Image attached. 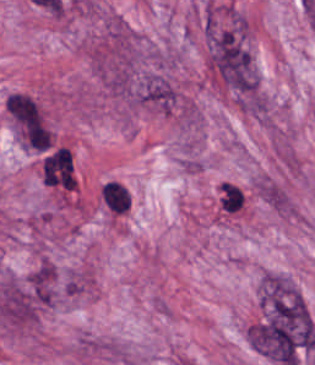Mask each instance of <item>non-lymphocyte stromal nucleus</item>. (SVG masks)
<instances>
[{
    "label": "non-lymphocyte stromal nucleus",
    "instance_id": "non-lymphocyte-stromal-nucleus-1",
    "mask_svg": "<svg viewBox=\"0 0 315 365\" xmlns=\"http://www.w3.org/2000/svg\"><path fill=\"white\" fill-rule=\"evenodd\" d=\"M7 109L23 144L36 151H46L51 136L35 98L22 91H15L7 97Z\"/></svg>",
    "mask_w": 315,
    "mask_h": 365
},
{
    "label": "non-lymphocyte stromal nucleus",
    "instance_id": "non-lymphocyte-stromal-nucleus-2",
    "mask_svg": "<svg viewBox=\"0 0 315 365\" xmlns=\"http://www.w3.org/2000/svg\"><path fill=\"white\" fill-rule=\"evenodd\" d=\"M42 181L74 189L73 160L68 148L61 146L45 159Z\"/></svg>",
    "mask_w": 315,
    "mask_h": 365
},
{
    "label": "non-lymphocyte stromal nucleus",
    "instance_id": "non-lymphocyte-stromal-nucleus-3",
    "mask_svg": "<svg viewBox=\"0 0 315 365\" xmlns=\"http://www.w3.org/2000/svg\"><path fill=\"white\" fill-rule=\"evenodd\" d=\"M105 205L115 214H123L130 207L129 192L116 181H108L100 189Z\"/></svg>",
    "mask_w": 315,
    "mask_h": 365
}]
</instances>
